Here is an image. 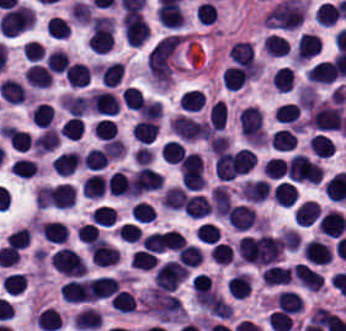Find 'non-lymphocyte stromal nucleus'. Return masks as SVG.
Returning a JSON list of instances; mask_svg holds the SVG:
<instances>
[{
	"label": "non-lymphocyte stromal nucleus",
	"mask_w": 346,
	"mask_h": 331,
	"mask_svg": "<svg viewBox=\"0 0 346 331\" xmlns=\"http://www.w3.org/2000/svg\"><path fill=\"white\" fill-rule=\"evenodd\" d=\"M180 43L181 36L175 33L156 43L148 52L149 78L164 89L171 82Z\"/></svg>",
	"instance_id": "non-lymphocyte-stromal-nucleus-1"
},
{
	"label": "non-lymphocyte stromal nucleus",
	"mask_w": 346,
	"mask_h": 331,
	"mask_svg": "<svg viewBox=\"0 0 346 331\" xmlns=\"http://www.w3.org/2000/svg\"><path fill=\"white\" fill-rule=\"evenodd\" d=\"M210 198H211V203H212L214 213H217L226 217L232 205V201L225 186L217 185L215 188H213L210 194Z\"/></svg>",
	"instance_id": "non-lymphocyte-stromal-nucleus-2"
}]
</instances>
